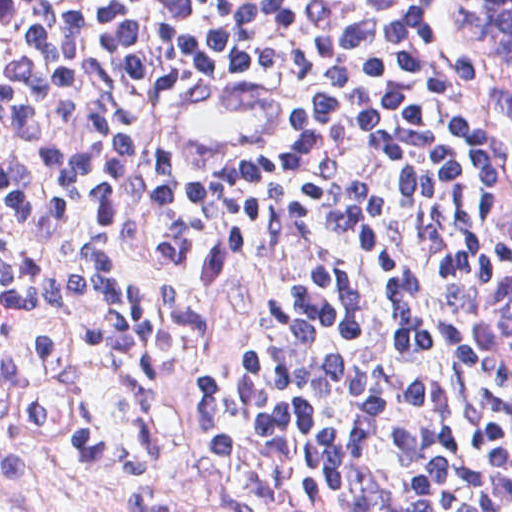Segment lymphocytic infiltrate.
Masks as SVG:
<instances>
[{
    "instance_id": "1",
    "label": "lymphocytic infiltrate",
    "mask_w": 512,
    "mask_h": 512,
    "mask_svg": "<svg viewBox=\"0 0 512 512\" xmlns=\"http://www.w3.org/2000/svg\"><path fill=\"white\" fill-rule=\"evenodd\" d=\"M253 71L293 141L180 136L177 78ZM0 259L190 388L248 512H512V413L471 366L474 292L512 268V96L443 55L435 0H0ZM32 310L0 266V394L42 455ZM56 466L179 486L86 423Z\"/></svg>"
}]
</instances>
